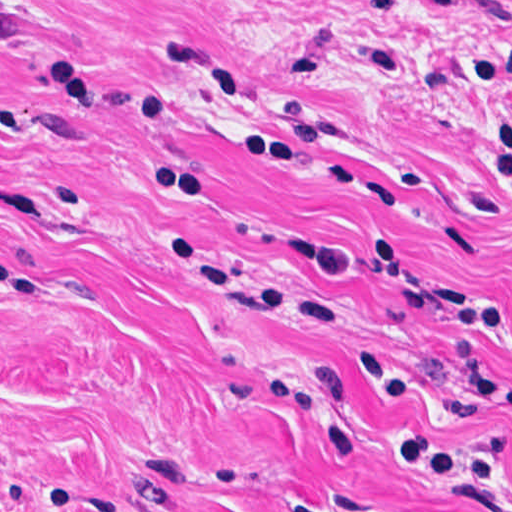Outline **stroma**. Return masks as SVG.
Wrapping results in <instances>:
<instances>
[{
	"label": "stroma",
	"instance_id": "1",
	"mask_svg": "<svg viewBox=\"0 0 512 512\" xmlns=\"http://www.w3.org/2000/svg\"><path fill=\"white\" fill-rule=\"evenodd\" d=\"M512 0H0V512H497Z\"/></svg>",
	"mask_w": 512,
	"mask_h": 512
}]
</instances>
